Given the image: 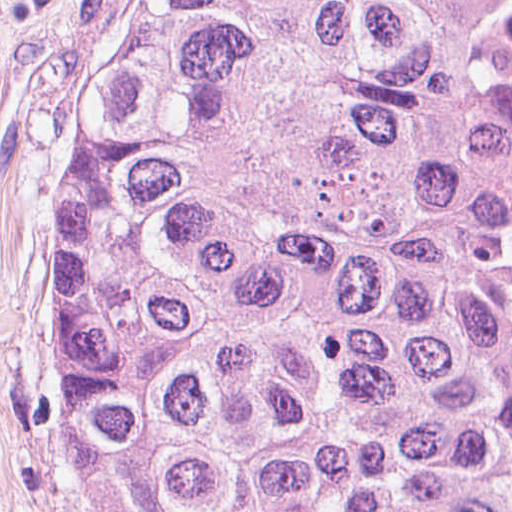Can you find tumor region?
I'll list each match as a JSON object with an SVG mask.
<instances>
[{
	"mask_svg": "<svg viewBox=\"0 0 512 512\" xmlns=\"http://www.w3.org/2000/svg\"><path fill=\"white\" fill-rule=\"evenodd\" d=\"M50 430L88 512H512V0H124Z\"/></svg>",
	"mask_w": 512,
	"mask_h": 512,
	"instance_id": "obj_1",
	"label": "tumor region"
}]
</instances>
